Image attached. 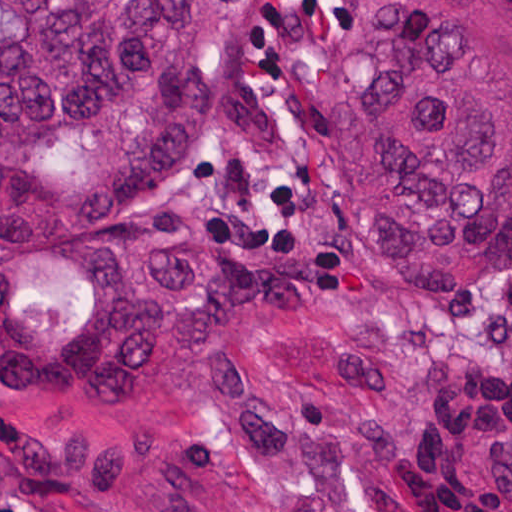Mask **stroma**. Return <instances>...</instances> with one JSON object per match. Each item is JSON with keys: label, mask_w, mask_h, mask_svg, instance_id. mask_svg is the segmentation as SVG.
Instances as JSON below:
<instances>
[{"label": "stroma", "mask_w": 512, "mask_h": 512, "mask_svg": "<svg viewBox=\"0 0 512 512\" xmlns=\"http://www.w3.org/2000/svg\"><path fill=\"white\" fill-rule=\"evenodd\" d=\"M351 2L256 0L153 199L84 239L0 256V353H34L70 322L88 254L120 229L199 220L261 242L342 236L318 163V98ZM394 349L421 393L392 458L408 512H512V270L455 295L394 294ZM0 512H15L1 474Z\"/></svg>", "instance_id": "1"}]
</instances>
